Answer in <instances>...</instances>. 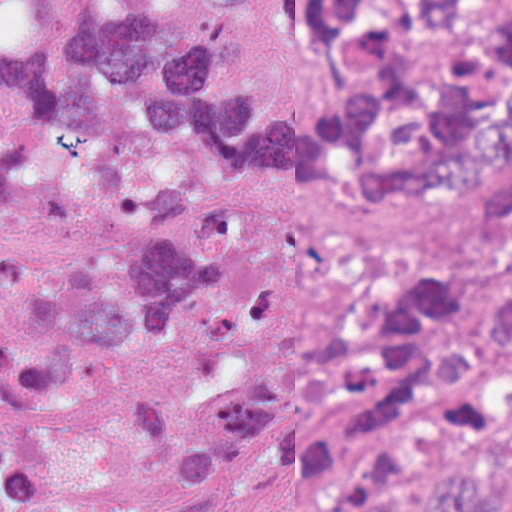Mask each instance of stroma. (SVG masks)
Returning <instances> with one entry per match:
<instances>
[{
	"mask_svg": "<svg viewBox=\"0 0 512 512\" xmlns=\"http://www.w3.org/2000/svg\"><path fill=\"white\" fill-rule=\"evenodd\" d=\"M240 64L272 91L311 102L322 59L300 38L287 0H244L236 19ZM77 195L116 235L158 243L194 201L236 196L253 215L256 256L271 270V316L253 332L195 338L156 355L86 361L83 382L56 416L69 481L111 512H183L184 487L146 465L124 425L142 389H203L280 361L304 335L342 314L354 290L392 271H457L482 246L465 209H336L290 205L274 188L197 158L189 197L169 217H118L77 179ZM303 476H255L216 512H312Z\"/></svg>",
	"mask_w": 512,
	"mask_h": 512,
	"instance_id": "stroma-1",
	"label": "stroma"
}]
</instances>
